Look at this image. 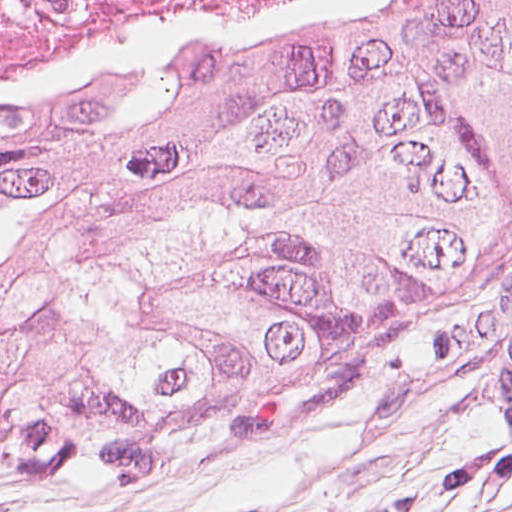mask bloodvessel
<instances>
[{"label": "blood vessel", "instance_id": "1", "mask_svg": "<svg viewBox=\"0 0 512 512\" xmlns=\"http://www.w3.org/2000/svg\"><path fill=\"white\" fill-rule=\"evenodd\" d=\"M499 409L512 437V317L502 329L499 346Z\"/></svg>", "mask_w": 512, "mask_h": 512}]
</instances>
